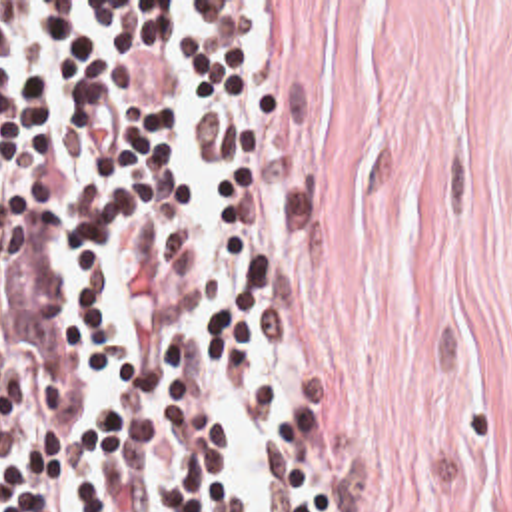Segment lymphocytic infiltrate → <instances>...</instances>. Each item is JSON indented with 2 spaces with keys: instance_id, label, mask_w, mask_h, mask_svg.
Segmentation results:
<instances>
[{
  "instance_id": "f902f5d3",
  "label": "lymphocytic infiltrate",
  "mask_w": 512,
  "mask_h": 512,
  "mask_svg": "<svg viewBox=\"0 0 512 512\" xmlns=\"http://www.w3.org/2000/svg\"><path fill=\"white\" fill-rule=\"evenodd\" d=\"M264 20L0 2V512H248L198 337L270 353L272 512H346L270 321Z\"/></svg>"
}]
</instances>
